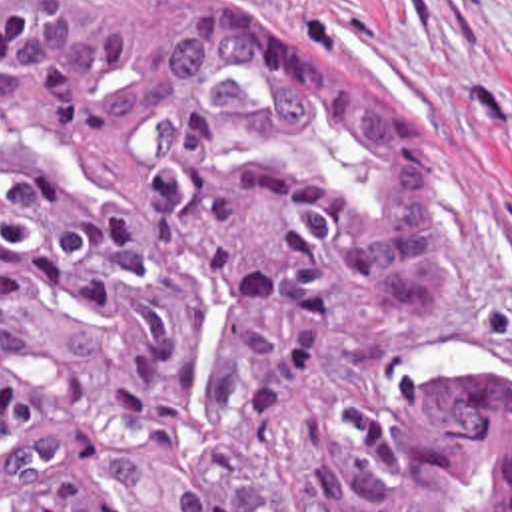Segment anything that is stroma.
<instances>
[{
  "mask_svg": "<svg viewBox=\"0 0 512 512\" xmlns=\"http://www.w3.org/2000/svg\"><path fill=\"white\" fill-rule=\"evenodd\" d=\"M330 43L386 99L442 203V289L400 363L450 343L512 355V0H246Z\"/></svg>",
  "mask_w": 512,
  "mask_h": 512,
  "instance_id": "obj_1",
  "label": "stroma"
}]
</instances>
